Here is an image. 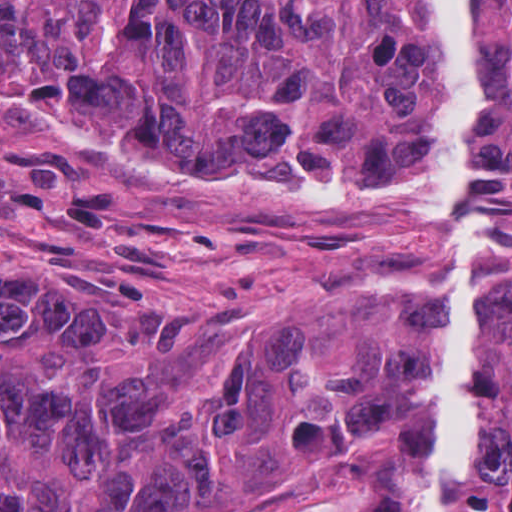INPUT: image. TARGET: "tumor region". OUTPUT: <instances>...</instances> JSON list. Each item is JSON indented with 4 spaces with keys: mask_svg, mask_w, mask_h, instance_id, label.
I'll return each mask as SVG.
<instances>
[{
    "mask_svg": "<svg viewBox=\"0 0 512 512\" xmlns=\"http://www.w3.org/2000/svg\"><path fill=\"white\" fill-rule=\"evenodd\" d=\"M468 8L477 216L512 225V0ZM446 114L420 0H0V127L80 163L435 213ZM480 325L512 338V292ZM420 370L388 334L323 368L285 312L110 343L70 295L0 284V508L185 512L244 440L291 466L407 428L413 460ZM456 512H512L511 369L481 366Z\"/></svg>",
    "mask_w": 512,
    "mask_h": 512,
    "instance_id": "tumor-region-1",
    "label": "tumor region"
}]
</instances>
